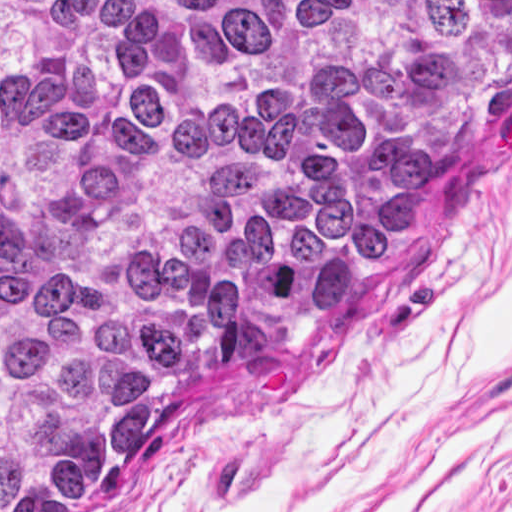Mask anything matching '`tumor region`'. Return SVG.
<instances>
[{
  "label": "tumor region",
  "mask_w": 512,
  "mask_h": 512,
  "mask_svg": "<svg viewBox=\"0 0 512 512\" xmlns=\"http://www.w3.org/2000/svg\"><path fill=\"white\" fill-rule=\"evenodd\" d=\"M512 122V0H0V512L288 349Z\"/></svg>",
  "instance_id": "tumor-region-1"
}]
</instances>
